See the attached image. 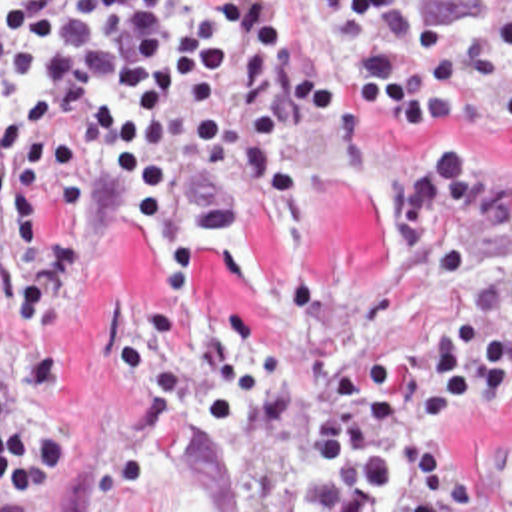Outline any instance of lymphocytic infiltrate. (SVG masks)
<instances>
[{"mask_svg": "<svg viewBox=\"0 0 512 512\" xmlns=\"http://www.w3.org/2000/svg\"><path fill=\"white\" fill-rule=\"evenodd\" d=\"M373 108L421 134L447 120L512 122V0L485 26L433 24L421 0H0V512H39L69 456L43 408L75 380L55 338L87 254L91 206L133 222L165 254L179 304L203 258L177 212L235 236L247 188L303 226L311 190L289 154L301 124ZM459 220L487 224L512 260V168L453 144L389 192L397 256ZM512 382V298L429 332L415 380L347 346L339 396L307 428L313 469H357L329 512H465L477 483L443 463L445 432Z\"/></svg>", "mask_w": 512, "mask_h": 512, "instance_id": "obj_1", "label": "lymphocytic infiltrate"}]
</instances>
